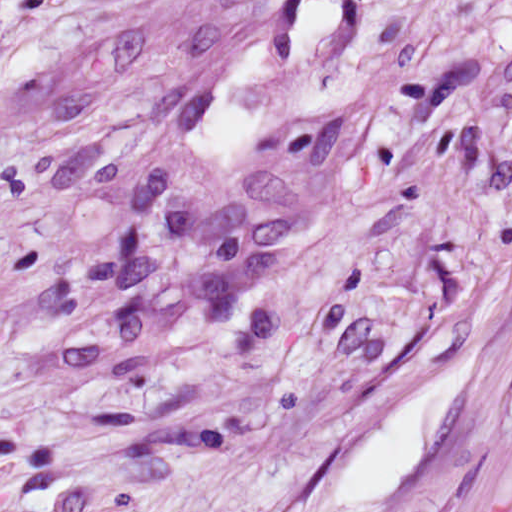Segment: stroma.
I'll return each mask as SVG.
<instances>
[{
  "instance_id": "35a3bbf8",
  "label": "stroma",
  "mask_w": 512,
  "mask_h": 512,
  "mask_svg": "<svg viewBox=\"0 0 512 512\" xmlns=\"http://www.w3.org/2000/svg\"><path fill=\"white\" fill-rule=\"evenodd\" d=\"M512 482V0H296Z\"/></svg>"
}]
</instances>
